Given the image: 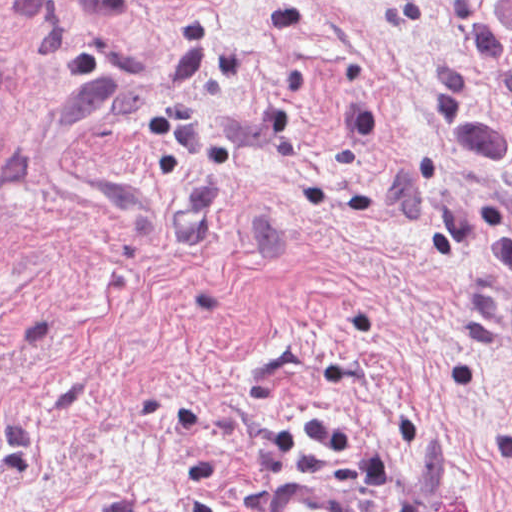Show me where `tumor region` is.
<instances>
[{"mask_svg": "<svg viewBox=\"0 0 512 512\" xmlns=\"http://www.w3.org/2000/svg\"><path fill=\"white\" fill-rule=\"evenodd\" d=\"M492 22L488 30V57L498 74L512 87V0H487Z\"/></svg>", "mask_w": 512, "mask_h": 512, "instance_id": "tumor-region-1", "label": "tumor region"}]
</instances>
